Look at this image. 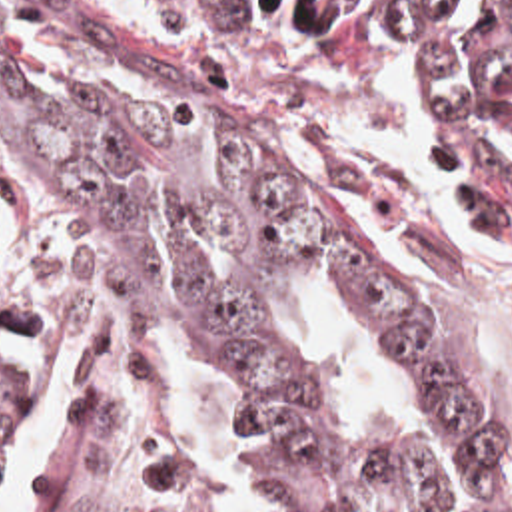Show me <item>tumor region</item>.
<instances>
[{"label":"tumor region","instance_id":"tumor-region-1","mask_svg":"<svg viewBox=\"0 0 512 512\" xmlns=\"http://www.w3.org/2000/svg\"><path fill=\"white\" fill-rule=\"evenodd\" d=\"M236 27L416 37L408 111L428 161L512 265V0H178ZM0 103L71 189L83 281L103 333L200 341L258 389L256 465L294 512H448V475L412 441L338 413L276 291H352L432 383L474 512H512V447L442 347L374 203L298 129L244 113L53 29L0 23ZM41 383L0 253V477ZM45 512H206L192 453L127 403L99 407Z\"/></svg>","mask_w":512,"mask_h":512}]
</instances>
